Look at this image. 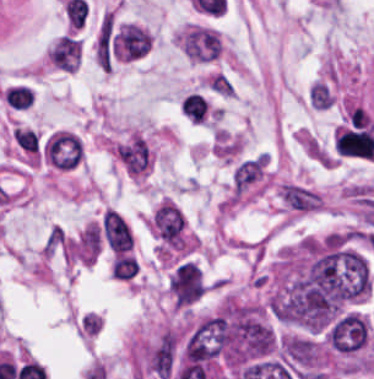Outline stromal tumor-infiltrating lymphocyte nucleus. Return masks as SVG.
I'll list each match as a JSON object with an SVG mask.
<instances>
[{"label":"stromal tumor-infiltrating lymphocyte nucleus","mask_w":374,"mask_h":379,"mask_svg":"<svg viewBox=\"0 0 374 379\" xmlns=\"http://www.w3.org/2000/svg\"><path fill=\"white\" fill-rule=\"evenodd\" d=\"M44 161L57 170H74L84 156V145L73 132L54 131L42 146Z\"/></svg>","instance_id":"obj_1"},{"label":"stromal tumor-infiltrating lymphocyte nucleus","mask_w":374,"mask_h":379,"mask_svg":"<svg viewBox=\"0 0 374 379\" xmlns=\"http://www.w3.org/2000/svg\"><path fill=\"white\" fill-rule=\"evenodd\" d=\"M181 113L194 123H202L209 118L210 103L198 91H191L182 98Z\"/></svg>","instance_id":"obj_2"}]
</instances>
